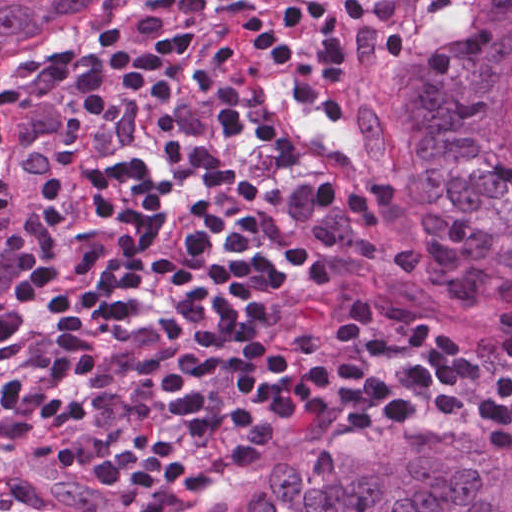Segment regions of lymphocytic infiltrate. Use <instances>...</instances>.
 Returning <instances> with one entry per match:
<instances>
[{
  "label": "lymphocytic infiltrate",
  "mask_w": 512,
  "mask_h": 512,
  "mask_svg": "<svg viewBox=\"0 0 512 512\" xmlns=\"http://www.w3.org/2000/svg\"><path fill=\"white\" fill-rule=\"evenodd\" d=\"M432 1L204 0L0 109V225L20 229L0 512H156L326 422L377 438L455 410L483 451L512 450V372L463 364L466 311L404 282L375 179L283 168L230 104L254 60L293 45L356 102L354 27L411 25Z\"/></svg>",
  "instance_id": "lymphocytic-infiltrate-1"
}]
</instances>
